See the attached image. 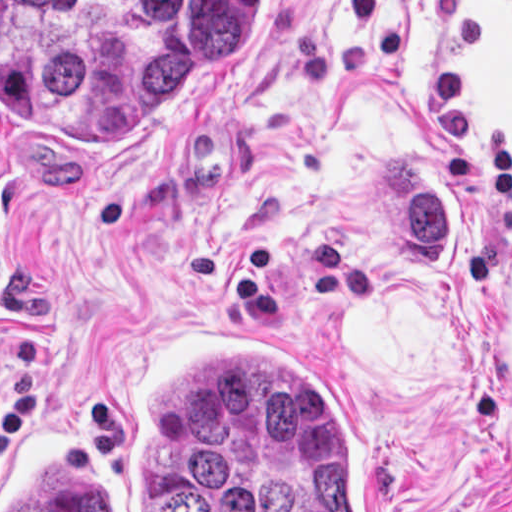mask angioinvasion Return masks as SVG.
Returning a JSON list of instances; mask_svg holds the SVG:
<instances>
[{"instance_id":"1","label":"angioinvasion","mask_w":512,"mask_h":512,"mask_svg":"<svg viewBox=\"0 0 512 512\" xmlns=\"http://www.w3.org/2000/svg\"><path fill=\"white\" fill-rule=\"evenodd\" d=\"M275 334L165 325L1 431V512H394L364 418Z\"/></svg>"}]
</instances>
